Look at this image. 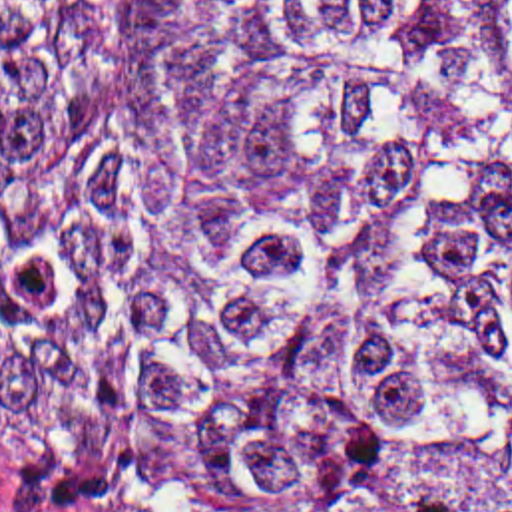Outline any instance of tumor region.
I'll use <instances>...</instances> for the list:
<instances>
[{"mask_svg":"<svg viewBox=\"0 0 512 512\" xmlns=\"http://www.w3.org/2000/svg\"><path fill=\"white\" fill-rule=\"evenodd\" d=\"M0 439L126 512H512V0H0Z\"/></svg>","mask_w":512,"mask_h":512,"instance_id":"obj_1","label":"tumor region"}]
</instances>
